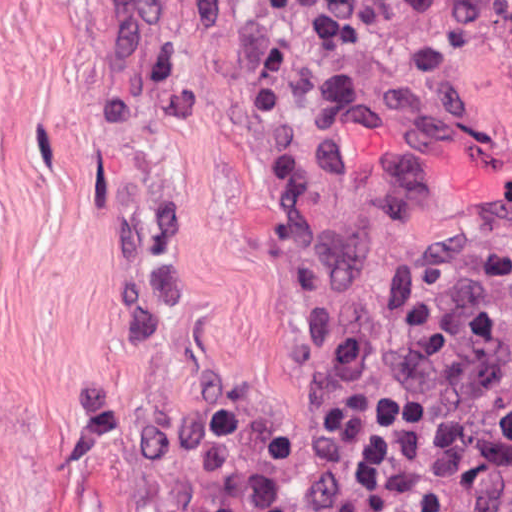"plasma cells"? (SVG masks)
<instances>
[{
  "label": "plasma cells",
  "instance_id": "plasma-cells-1",
  "mask_svg": "<svg viewBox=\"0 0 512 512\" xmlns=\"http://www.w3.org/2000/svg\"><path fill=\"white\" fill-rule=\"evenodd\" d=\"M263 6L302 37H343L352 0H247ZM466 512H512V435L489 465Z\"/></svg>",
  "mask_w": 512,
  "mask_h": 512
}]
</instances>
